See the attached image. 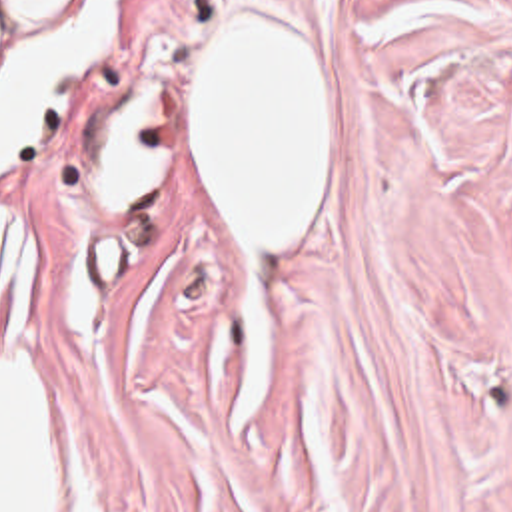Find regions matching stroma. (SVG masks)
Wrapping results in <instances>:
<instances>
[{"label":"stroma","instance_id":"1","mask_svg":"<svg viewBox=\"0 0 512 512\" xmlns=\"http://www.w3.org/2000/svg\"><path fill=\"white\" fill-rule=\"evenodd\" d=\"M236 9L328 51L298 247L242 241L210 179L194 71ZM138 83L156 195L120 237L92 157ZM0 211L62 512H512V0H118Z\"/></svg>","mask_w":512,"mask_h":512}]
</instances>
